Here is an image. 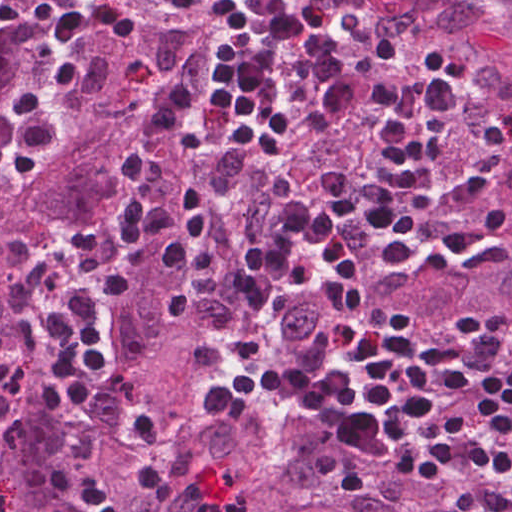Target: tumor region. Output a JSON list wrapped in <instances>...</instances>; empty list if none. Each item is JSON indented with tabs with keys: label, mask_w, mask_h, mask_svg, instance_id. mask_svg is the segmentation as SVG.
I'll return each mask as SVG.
<instances>
[{
	"label": "tumor region",
	"mask_w": 512,
	"mask_h": 512,
	"mask_svg": "<svg viewBox=\"0 0 512 512\" xmlns=\"http://www.w3.org/2000/svg\"><path fill=\"white\" fill-rule=\"evenodd\" d=\"M371 1L512 127V0L470 8Z\"/></svg>",
	"instance_id": "1"
}]
</instances>
